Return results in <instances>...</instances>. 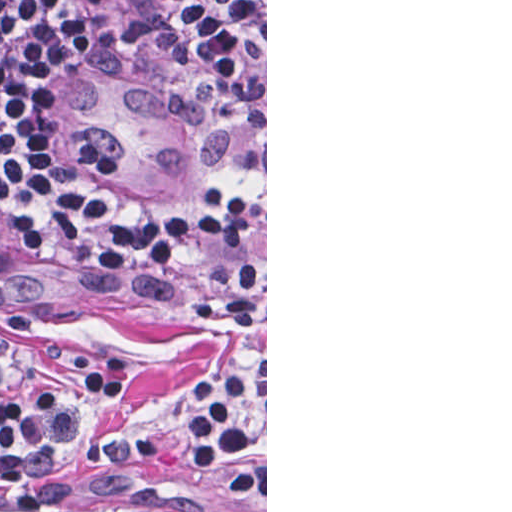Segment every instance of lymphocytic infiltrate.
<instances>
[{
    "mask_svg": "<svg viewBox=\"0 0 512 512\" xmlns=\"http://www.w3.org/2000/svg\"><path fill=\"white\" fill-rule=\"evenodd\" d=\"M218 59L266 86V10L253 0H175ZM32 0H0V232L79 249L139 253L187 275L205 318L254 329L265 300L266 210L249 190L201 195L196 223L123 209L91 192L43 144L30 112ZM135 372L114 350L86 344L66 366L26 381L0 361V512L58 506L63 462L129 419ZM184 464L218 512H249L266 489V383L232 358L178 400Z\"/></svg>",
    "mask_w": 512,
    "mask_h": 512,
    "instance_id": "lymphocytic-infiltrate-1",
    "label": "lymphocytic infiltrate"
}]
</instances>
